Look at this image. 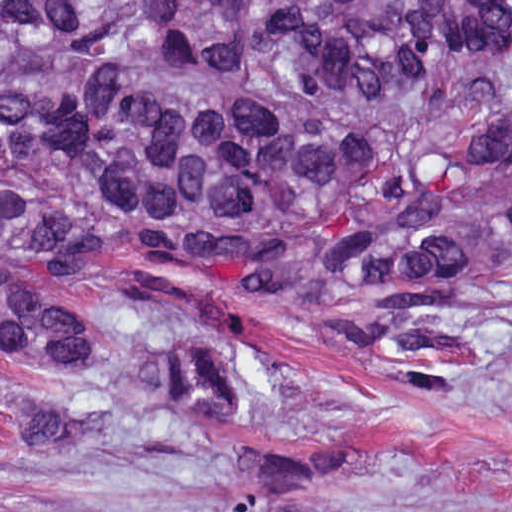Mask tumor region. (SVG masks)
<instances>
[{"instance_id":"tumor-region-1","label":"tumor region","mask_w":512,"mask_h":512,"mask_svg":"<svg viewBox=\"0 0 512 512\" xmlns=\"http://www.w3.org/2000/svg\"><path fill=\"white\" fill-rule=\"evenodd\" d=\"M512 1H0V433L93 449L119 426L235 444L271 386L205 308L82 305L1 261H155L315 304L314 336L440 396L512 339ZM349 431L258 440L161 512H512L344 496ZM63 512H115L78 507Z\"/></svg>"}]
</instances>
